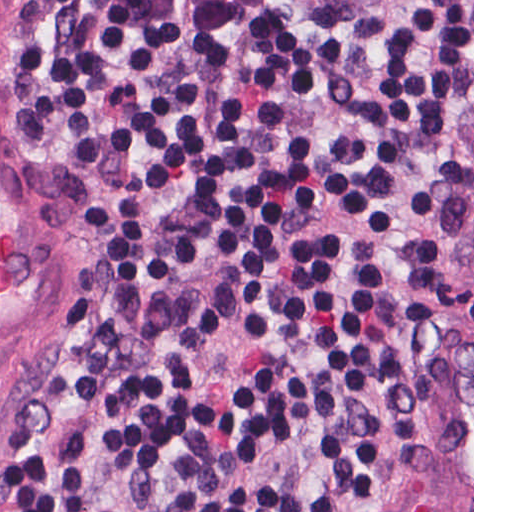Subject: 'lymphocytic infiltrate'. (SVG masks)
<instances>
[{"label": "lymphocytic infiltrate", "instance_id": "f902f5d3", "mask_svg": "<svg viewBox=\"0 0 512 512\" xmlns=\"http://www.w3.org/2000/svg\"><path fill=\"white\" fill-rule=\"evenodd\" d=\"M32 143L104 250L3 512H360L472 419V0H45Z\"/></svg>", "mask_w": 512, "mask_h": 512}]
</instances>
